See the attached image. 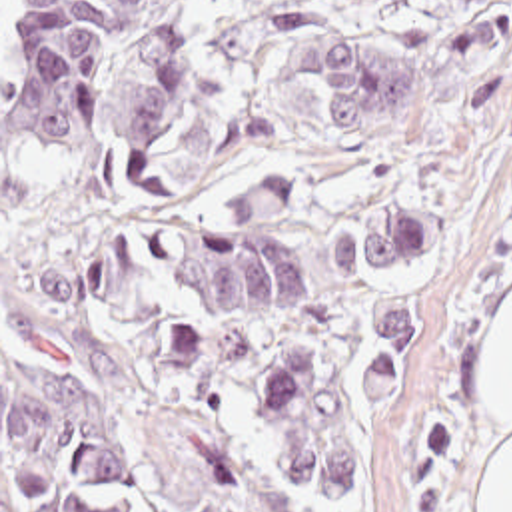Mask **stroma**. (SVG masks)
Masks as SVG:
<instances>
[{"mask_svg":"<svg viewBox=\"0 0 512 512\" xmlns=\"http://www.w3.org/2000/svg\"><path fill=\"white\" fill-rule=\"evenodd\" d=\"M210 186L222 208L291 172L299 262L311 304L268 326L224 330L238 378L273 354L321 360L371 481V511L301 489L273 461L254 415L234 410L244 512H481L505 427L489 414V322L512 296V42L509 108L459 122V70L435 0H190ZM337 28L403 48L419 72L417 132H327L301 38ZM417 202L445 246L393 270L335 264L343 220ZM419 306V362L387 410L359 394L351 364L369 316Z\"/></svg>","mask_w":512,"mask_h":512,"instance_id":"stroma-1","label":"stroma"}]
</instances>
